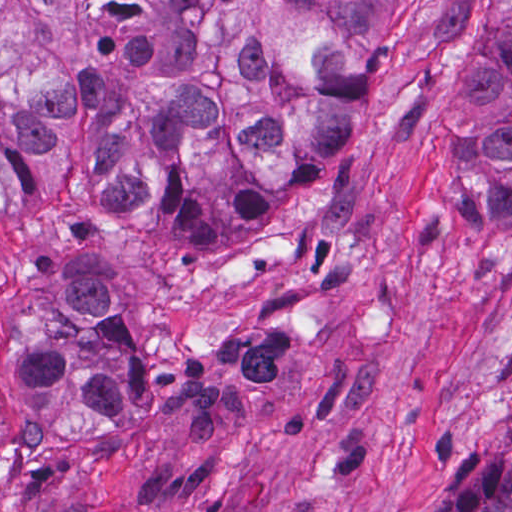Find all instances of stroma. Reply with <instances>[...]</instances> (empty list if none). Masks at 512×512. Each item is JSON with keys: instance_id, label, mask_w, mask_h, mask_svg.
I'll return each instance as SVG.
<instances>
[{"instance_id": "35a3bbf8", "label": "stroma", "mask_w": 512, "mask_h": 512, "mask_svg": "<svg viewBox=\"0 0 512 512\" xmlns=\"http://www.w3.org/2000/svg\"><path fill=\"white\" fill-rule=\"evenodd\" d=\"M448 49H380L364 131L135 314V411L1 442L0 512H444L512 428V226L435 223L475 176L464 94L500 0Z\"/></svg>"}]
</instances>
